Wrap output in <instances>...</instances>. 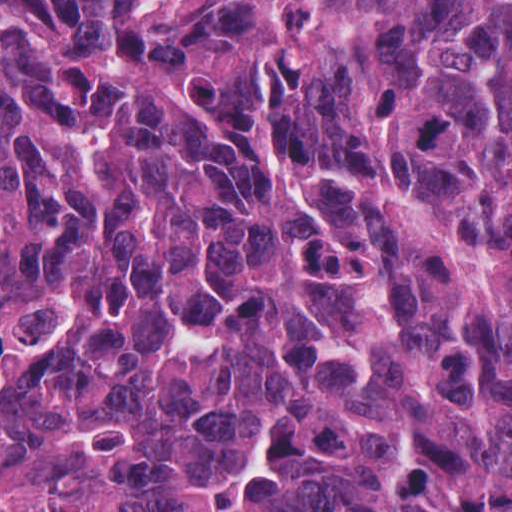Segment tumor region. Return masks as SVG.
<instances>
[{
    "label": "tumor region",
    "instance_id": "1",
    "mask_svg": "<svg viewBox=\"0 0 512 512\" xmlns=\"http://www.w3.org/2000/svg\"><path fill=\"white\" fill-rule=\"evenodd\" d=\"M0 512H512V0H0Z\"/></svg>",
    "mask_w": 512,
    "mask_h": 512
}]
</instances>
